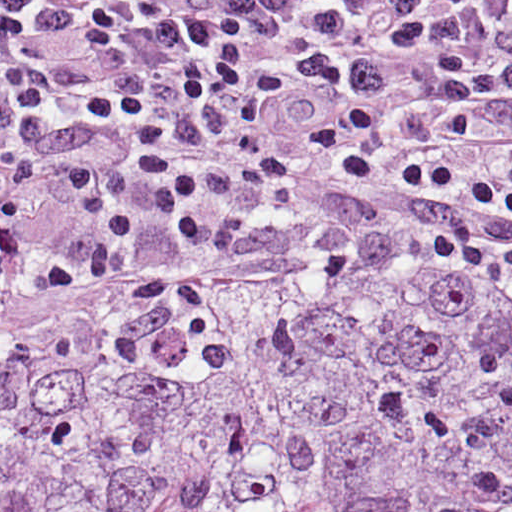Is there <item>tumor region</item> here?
Segmentation results:
<instances>
[{"mask_svg": "<svg viewBox=\"0 0 512 512\" xmlns=\"http://www.w3.org/2000/svg\"><path fill=\"white\" fill-rule=\"evenodd\" d=\"M0 512H512V269L354 241L7 320Z\"/></svg>", "mask_w": 512, "mask_h": 512, "instance_id": "obj_1", "label": "tumor region"}]
</instances>
